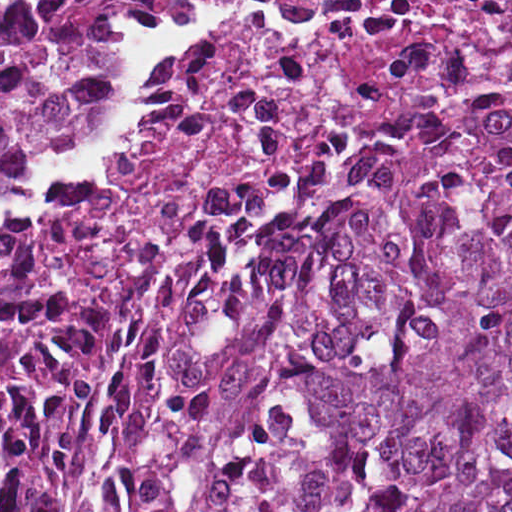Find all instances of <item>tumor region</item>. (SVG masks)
Listing matches in <instances>:
<instances>
[{
    "label": "tumor region",
    "mask_w": 512,
    "mask_h": 512,
    "mask_svg": "<svg viewBox=\"0 0 512 512\" xmlns=\"http://www.w3.org/2000/svg\"><path fill=\"white\" fill-rule=\"evenodd\" d=\"M161 1L0 0V190L106 128ZM0 512H512V85L394 111L98 319L0 232Z\"/></svg>",
    "instance_id": "e687c5a6"
}]
</instances>
